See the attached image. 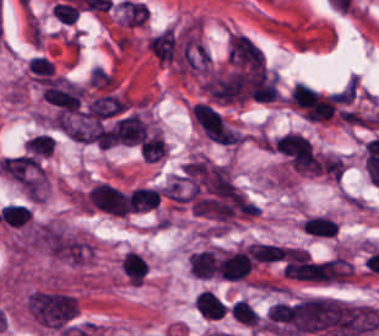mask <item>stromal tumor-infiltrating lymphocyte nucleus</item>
<instances>
[{
	"label": "stromal tumor-infiltrating lymphocyte nucleus",
	"instance_id": "3290ff9b",
	"mask_svg": "<svg viewBox=\"0 0 379 336\" xmlns=\"http://www.w3.org/2000/svg\"><path fill=\"white\" fill-rule=\"evenodd\" d=\"M300 226L305 234L318 239L335 237L338 229L334 217L324 212H311Z\"/></svg>",
	"mask_w": 379,
	"mask_h": 336
},
{
	"label": "stromal tumor-infiltrating lymphocyte nucleus",
	"instance_id": "9ea309e8",
	"mask_svg": "<svg viewBox=\"0 0 379 336\" xmlns=\"http://www.w3.org/2000/svg\"><path fill=\"white\" fill-rule=\"evenodd\" d=\"M54 150V136L49 133H36L28 137L22 153L43 161L52 155Z\"/></svg>",
	"mask_w": 379,
	"mask_h": 336
},
{
	"label": "stromal tumor-infiltrating lymphocyte nucleus",
	"instance_id": "bc302bb0",
	"mask_svg": "<svg viewBox=\"0 0 379 336\" xmlns=\"http://www.w3.org/2000/svg\"><path fill=\"white\" fill-rule=\"evenodd\" d=\"M84 204L88 210L112 216H127L131 211L130 202L123 190L104 180L94 183Z\"/></svg>",
	"mask_w": 379,
	"mask_h": 336
},
{
	"label": "stromal tumor-infiltrating lymphocyte nucleus",
	"instance_id": "52c7bb5b",
	"mask_svg": "<svg viewBox=\"0 0 379 336\" xmlns=\"http://www.w3.org/2000/svg\"><path fill=\"white\" fill-rule=\"evenodd\" d=\"M255 263L245 248H223L220 252L218 275L224 280H243Z\"/></svg>",
	"mask_w": 379,
	"mask_h": 336
},
{
	"label": "stromal tumor-infiltrating lymphocyte nucleus",
	"instance_id": "4803ca6d",
	"mask_svg": "<svg viewBox=\"0 0 379 336\" xmlns=\"http://www.w3.org/2000/svg\"><path fill=\"white\" fill-rule=\"evenodd\" d=\"M51 12L63 23H73L79 13V6L71 1H57L52 4Z\"/></svg>",
	"mask_w": 379,
	"mask_h": 336
},
{
	"label": "stromal tumor-infiltrating lymphocyte nucleus",
	"instance_id": "f3e2335f",
	"mask_svg": "<svg viewBox=\"0 0 379 336\" xmlns=\"http://www.w3.org/2000/svg\"><path fill=\"white\" fill-rule=\"evenodd\" d=\"M127 195L135 212L152 210L159 205L160 195L157 188L135 187Z\"/></svg>",
	"mask_w": 379,
	"mask_h": 336
},
{
	"label": "stromal tumor-infiltrating lymphocyte nucleus",
	"instance_id": "2a367800",
	"mask_svg": "<svg viewBox=\"0 0 379 336\" xmlns=\"http://www.w3.org/2000/svg\"><path fill=\"white\" fill-rule=\"evenodd\" d=\"M229 312L232 317L245 324L258 326L260 316L256 309L244 298H237L229 307Z\"/></svg>",
	"mask_w": 379,
	"mask_h": 336
},
{
	"label": "stromal tumor-infiltrating lymphocyte nucleus",
	"instance_id": "abfb95fc",
	"mask_svg": "<svg viewBox=\"0 0 379 336\" xmlns=\"http://www.w3.org/2000/svg\"><path fill=\"white\" fill-rule=\"evenodd\" d=\"M196 308L205 318H218L229 309L225 302L211 290L200 291L196 296Z\"/></svg>",
	"mask_w": 379,
	"mask_h": 336
},
{
	"label": "stromal tumor-infiltrating lymphocyte nucleus",
	"instance_id": "4f13568d",
	"mask_svg": "<svg viewBox=\"0 0 379 336\" xmlns=\"http://www.w3.org/2000/svg\"><path fill=\"white\" fill-rule=\"evenodd\" d=\"M26 66L32 80L36 82L44 83L54 75L52 60H50L46 55H32Z\"/></svg>",
	"mask_w": 379,
	"mask_h": 336
}]
</instances>
